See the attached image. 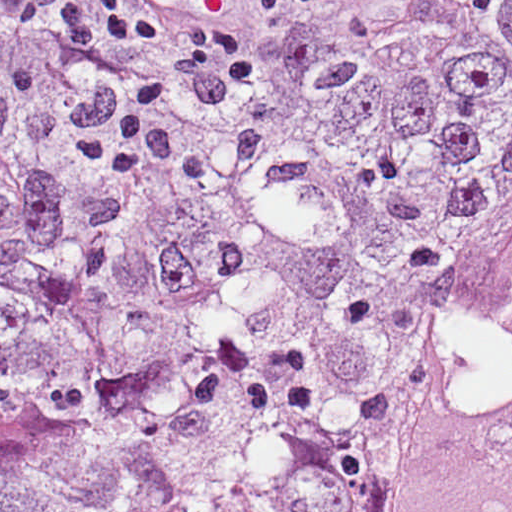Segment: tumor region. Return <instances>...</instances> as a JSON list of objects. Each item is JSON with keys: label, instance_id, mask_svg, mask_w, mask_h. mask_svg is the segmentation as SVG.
Here are the masks:
<instances>
[{"label": "tumor region", "instance_id": "1", "mask_svg": "<svg viewBox=\"0 0 512 512\" xmlns=\"http://www.w3.org/2000/svg\"><path fill=\"white\" fill-rule=\"evenodd\" d=\"M512 268V0H274L0 219V512H389Z\"/></svg>", "mask_w": 512, "mask_h": 512}]
</instances>
